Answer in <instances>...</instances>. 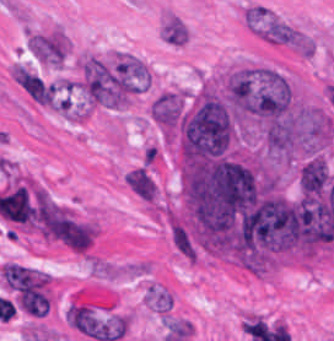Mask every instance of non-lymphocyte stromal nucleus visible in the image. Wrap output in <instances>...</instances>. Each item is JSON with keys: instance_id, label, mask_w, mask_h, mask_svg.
I'll return each instance as SVG.
<instances>
[{"instance_id": "6", "label": "non-lymphocyte stromal nucleus", "mask_w": 334, "mask_h": 341, "mask_svg": "<svg viewBox=\"0 0 334 341\" xmlns=\"http://www.w3.org/2000/svg\"><path fill=\"white\" fill-rule=\"evenodd\" d=\"M16 83L35 101L51 103L53 87L35 73L14 64L11 68Z\"/></svg>"}, {"instance_id": "5", "label": "non-lymphocyte stromal nucleus", "mask_w": 334, "mask_h": 341, "mask_svg": "<svg viewBox=\"0 0 334 341\" xmlns=\"http://www.w3.org/2000/svg\"><path fill=\"white\" fill-rule=\"evenodd\" d=\"M27 48L39 62L60 64L66 53V41L59 31L53 30L31 35Z\"/></svg>"}, {"instance_id": "3", "label": "non-lymphocyte stromal nucleus", "mask_w": 334, "mask_h": 341, "mask_svg": "<svg viewBox=\"0 0 334 341\" xmlns=\"http://www.w3.org/2000/svg\"><path fill=\"white\" fill-rule=\"evenodd\" d=\"M48 240L73 249L87 251L96 232L93 225L64 212L47 224Z\"/></svg>"}, {"instance_id": "1", "label": "non-lymphocyte stromal nucleus", "mask_w": 334, "mask_h": 341, "mask_svg": "<svg viewBox=\"0 0 334 341\" xmlns=\"http://www.w3.org/2000/svg\"><path fill=\"white\" fill-rule=\"evenodd\" d=\"M1 275L23 310L39 316L49 310V277L43 271L7 262Z\"/></svg>"}, {"instance_id": "2", "label": "non-lymphocyte stromal nucleus", "mask_w": 334, "mask_h": 341, "mask_svg": "<svg viewBox=\"0 0 334 341\" xmlns=\"http://www.w3.org/2000/svg\"><path fill=\"white\" fill-rule=\"evenodd\" d=\"M240 21L252 36L262 40H287L286 18L268 4L254 1L242 3Z\"/></svg>"}, {"instance_id": "7", "label": "non-lymphocyte stromal nucleus", "mask_w": 334, "mask_h": 341, "mask_svg": "<svg viewBox=\"0 0 334 341\" xmlns=\"http://www.w3.org/2000/svg\"><path fill=\"white\" fill-rule=\"evenodd\" d=\"M161 39L182 45L187 40V31L177 17L170 15L162 24Z\"/></svg>"}, {"instance_id": "4", "label": "non-lymphocyte stromal nucleus", "mask_w": 334, "mask_h": 341, "mask_svg": "<svg viewBox=\"0 0 334 341\" xmlns=\"http://www.w3.org/2000/svg\"><path fill=\"white\" fill-rule=\"evenodd\" d=\"M262 41L297 57L307 58L312 55L311 38L304 30L290 22Z\"/></svg>"}, {"instance_id": "8", "label": "non-lymphocyte stromal nucleus", "mask_w": 334, "mask_h": 341, "mask_svg": "<svg viewBox=\"0 0 334 341\" xmlns=\"http://www.w3.org/2000/svg\"><path fill=\"white\" fill-rule=\"evenodd\" d=\"M145 300L147 304L159 311L161 314L171 306L169 294L157 286L147 288Z\"/></svg>"}]
</instances>
